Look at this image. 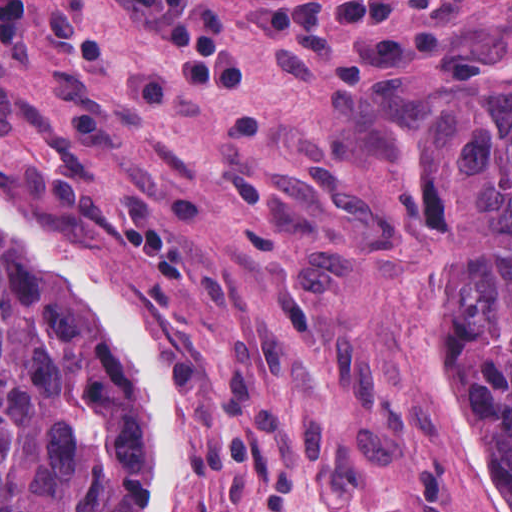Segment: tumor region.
Masks as SVG:
<instances>
[{
  "label": "tumor region",
  "instance_id": "1",
  "mask_svg": "<svg viewBox=\"0 0 512 512\" xmlns=\"http://www.w3.org/2000/svg\"><path fill=\"white\" fill-rule=\"evenodd\" d=\"M397 234L426 298L434 407L467 411L512 490V73L400 165ZM141 458L136 413L0 258V512H124Z\"/></svg>",
  "mask_w": 512,
  "mask_h": 512
}]
</instances>
